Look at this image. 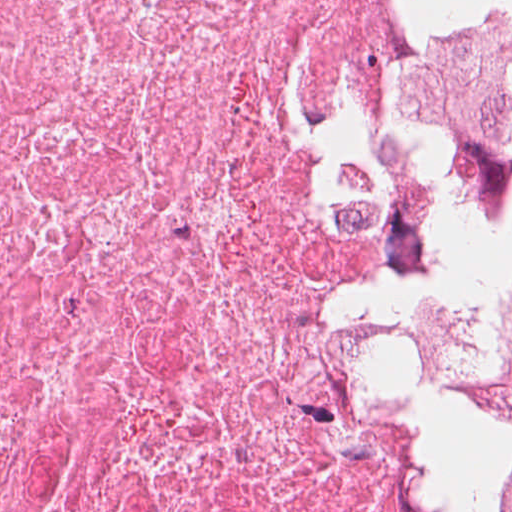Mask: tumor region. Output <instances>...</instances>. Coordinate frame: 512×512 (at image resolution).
Here are the masks:
<instances>
[{
	"label": "tumor region",
	"mask_w": 512,
	"mask_h": 512,
	"mask_svg": "<svg viewBox=\"0 0 512 512\" xmlns=\"http://www.w3.org/2000/svg\"><path fill=\"white\" fill-rule=\"evenodd\" d=\"M449 322L458 362L415 450L430 462L419 512H512V208L485 264L455 285Z\"/></svg>",
	"instance_id": "tumor-region-1"
}]
</instances>
